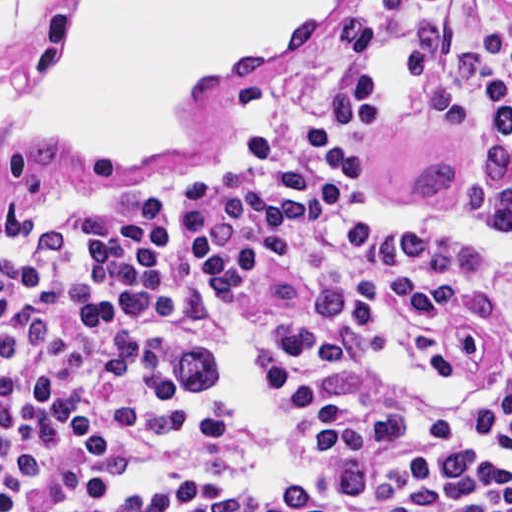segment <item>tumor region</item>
Returning <instances> with one entry per match:
<instances>
[{
  "label": "tumor region",
  "instance_id": "tumor-region-1",
  "mask_svg": "<svg viewBox=\"0 0 512 512\" xmlns=\"http://www.w3.org/2000/svg\"><path fill=\"white\" fill-rule=\"evenodd\" d=\"M327 30L359 53H373L380 47V28L357 16L340 17ZM169 362L174 378L187 389H210L221 376V361L213 347L200 338L182 343Z\"/></svg>",
  "mask_w": 512,
  "mask_h": 512
}]
</instances>
